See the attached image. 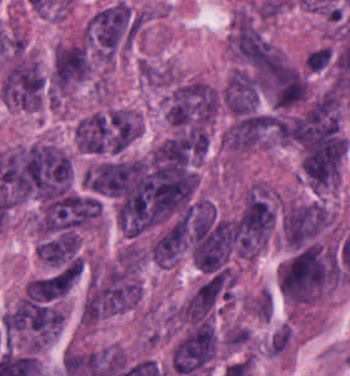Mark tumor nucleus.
<instances>
[{"instance_id": "2f306a5c", "label": "tumor nucleus", "mask_w": 350, "mask_h": 376, "mask_svg": "<svg viewBox=\"0 0 350 376\" xmlns=\"http://www.w3.org/2000/svg\"><path fill=\"white\" fill-rule=\"evenodd\" d=\"M236 53L259 93L279 108L302 100V73L264 39L235 32Z\"/></svg>"}, {"instance_id": "8643909e", "label": "tumor nucleus", "mask_w": 350, "mask_h": 376, "mask_svg": "<svg viewBox=\"0 0 350 376\" xmlns=\"http://www.w3.org/2000/svg\"><path fill=\"white\" fill-rule=\"evenodd\" d=\"M72 163L47 142L18 148L12 192L15 200H44L69 191Z\"/></svg>"}, {"instance_id": "5ab6c2c4", "label": "tumor nucleus", "mask_w": 350, "mask_h": 376, "mask_svg": "<svg viewBox=\"0 0 350 376\" xmlns=\"http://www.w3.org/2000/svg\"><path fill=\"white\" fill-rule=\"evenodd\" d=\"M333 283V254L314 243L291 251L280 268V291L288 303L307 304Z\"/></svg>"}, {"instance_id": "2cbd58db", "label": "tumor nucleus", "mask_w": 350, "mask_h": 376, "mask_svg": "<svg viewBox=\"0 0 350 376\" xmlns=\"http://www.w3.org/2000/svg\"><path fill=\"white\" fill-rule=\"evenodd\" d=\"M217 343L210 319H197L175 344L172 369L184 376L197 374L211 362Z\"/></svg>"}, {"instance_id": "3d1891a8", "label": "tumor nucleus", "mask_w": 350, "mask_h": 376, "mask_svg": "<svg viewBox=\"0 0 350 376\" xmlns=\"http://www.w3.org/2000/svg\"><path fill=\"white\" fill-rule=\"evenodd\" d=\"M328 220L321 200L286 204L281 217V236L287 248L295 249L312 241Z\"/></svg>"}, {"instance_id": "2083b535", "label": "tumor nucleus", "mask_w": 350, "mask_h": 376, "mask_svg": "<svg viewBox=\"0 0 350 376\" xmlns=\"http://www.w3.org/2000/svg\"><path fill=\"white\" fill-rule=\"evenodd\" d=\"M44 80L35 61L12 60L2 78L0 96L8 104L36 109L42 98Z\"/></svg>"}, {"instance_id": "8087334f", "label": "tumor nucleus", "mask_w": 350, "mask_h": 376, "mask_svg": "<svg viewBox=\"0 0 350 376\" xmlns=\"http://www.w3.org/2000/svg\"><path fill=\"white\" fill-rule=\"evenodd\" d=\"M258 91L252 75L237 70L226 82L223 104L233 115L243 116L257 109Z\"/></svg>"}, {"instance_id": "c2bd9aea", "label": "tumor nucleus", "mask_w": 350, "mask_h": 376, "mask_svg": "<svg viewBox=\"0 0 350 376\" xmlns=\"http://www.w3.org/2000/svg\"><path fill=\"white\" fill-rule=\"evenodd\" d=\"M71 279L65 273H56L33 279L25 285L24 295L34 300H48L63 295Z\"/></svg>"}, {"instance_id": "feef74b5", "label": "tumor nucleus", "mask_w": 350, "mask_h": 376, "mask_svg": "<svg viewBox=\"0 0 350 376\" xmlns=\"http://www.w3.org/2000/svg\"><path fill=\"white\" fill-rule=\"evenodd\" d=\"M37 253L51 262L60 263L66 256V248L62 241L57 239L45 240L38 244Z\"/></svg>"}, {"instance_id": "3e47fb67", "label": "tumor nucleus", "mask_w": 350, "mask_h": 376, "mask_svg": "<svg viewBox=\"0 0 350 376\" xmlns=\"http://www.w3.org/2000/svg\"><path fill=\"white\" fill-rule=\"evenodd\" d=\"M333 59L332 47L321 45L306 55V62L309 67L315 70L326 69Z\"/></svg>"}]
</instances>
